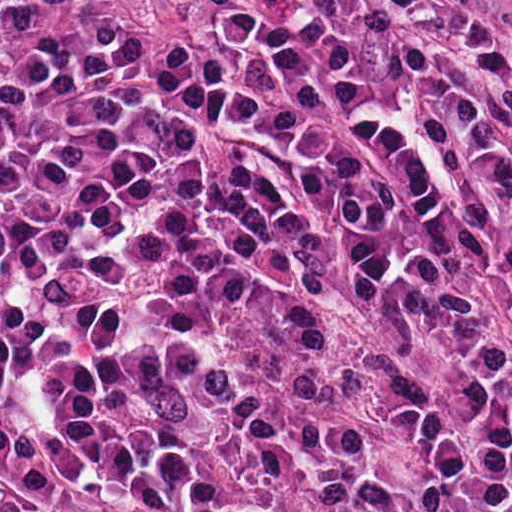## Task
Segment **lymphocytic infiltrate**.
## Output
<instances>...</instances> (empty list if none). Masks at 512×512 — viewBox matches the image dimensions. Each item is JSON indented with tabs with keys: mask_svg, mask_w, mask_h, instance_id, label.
<instances>
[{
	"mask_svg": "<svg viewBox=\"0 0 512 512\" xmlns=\"http://www.w3.org/2000/svg\"><path fill=\"white\" fill-rule=\"evenodd\" d=\"M0 368L182 512H512L507 0H0Z\"/></svg>",
	"mask_w": 512,
	"mask_h": 512,
	"instance_id": "lymphocytic-infiltrate-1",
	"label": "lymphocytic infiltrate"
}]
</instances>
